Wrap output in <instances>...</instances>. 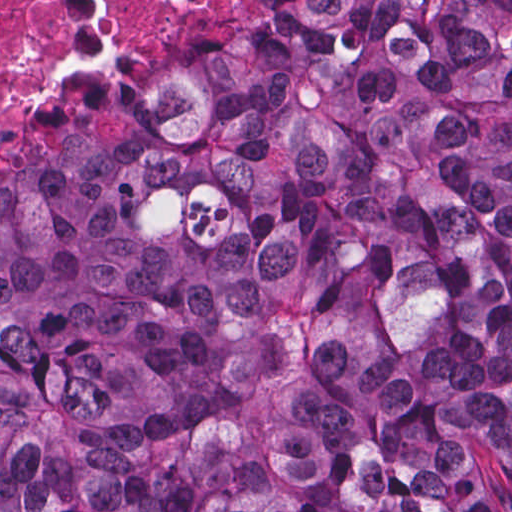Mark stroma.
I'll return each instance as SVG.
<instances>
[{
	"label": "stroma",
	"instance_id": "stroma-1",
	"mask_svg": "<svg viewBox=\"0 0 512 512\" xmlns=\"http://www.w3.org/2000/svg\"><path fill=\"white\" fill-rule=\"evenodd\" d=\"M269 1L249 0L233 13H192L158 40L97 44L82 56L61 60L37 88L17 126L0 138V184L48 162L128 84L215 39Z\"/></svg>",
	"mask_w": 512,
	"mask_h": 512
}]
</instances>
